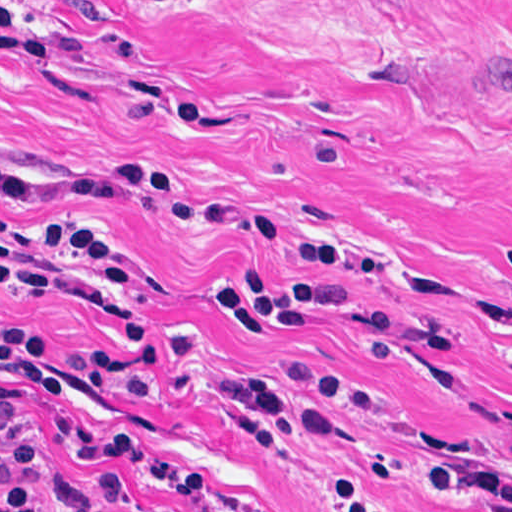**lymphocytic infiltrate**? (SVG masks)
I'll list each match as a JSON object with an SVG mask.
<instances>
[{
  "label": "lymphocytic infiltrate",
  "mask_w": 512,
  "mask_h": 512,
  "mask_svg": "<svg viewBox=\"0 0 512 512\" xmlns=\"http://www.w3.org/2000/svg\"><path fill=\"white\" fill-rule=\"evenodd\" d=\"M502 11L512 13V10ZM144 195H165L170 201L172 218L194 229L241 237L255 245L276 249L296 261L342 274L406 285L394 262L371 250L312 242L287 226L238 216L199 199L157 172L124 170L103 178L29 179L11 171L0 159V202L4 205L28 208L139 205V197ZM19 232L51 248L75 266L135 290L132 264L126 254L87 222L52 217ZM0 284L12 288L1 270ZM214 287L226 313L243 329L238 338H264L273 331H310L317 327V318L322 313L349 309L353 304L351 291L339 281L269 279L251 268L220 271L215 276ZM132 340L137 338L125 334V346ZM56 347L39 333L0 326V414L11 412L27 421L35 407L62 394L60 378L51 377L43 370L44 359ZM81 353L99 388L108 395L120 403H135L142 398L143 382L126 360L125 351ZM376 385L391 406L384 384ZM95 448L165 460L142 434L127 428L80 431L70 439L61 468L50 477L42 473L53 506H62L68 499L75 458ZM416 455L463 496H494L512 505V469L453 459L434 450ZM173 465L200 478L188 469ZM35 505L31 470L0 444V512H46Z\"/></svg>",
  "instance_id": "1"
}]
</instances>
